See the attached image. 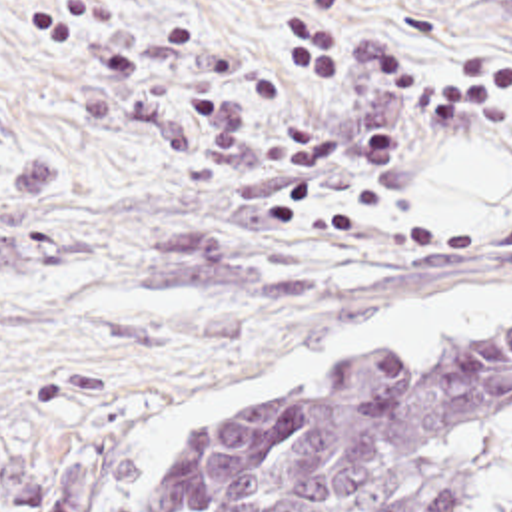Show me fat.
Wrapping results in <instances>:
<instances>
[{"mask_svg":"<svg viewBox=\"0 0 512 512\" xmlns=\"http://www.w3.org/2000/svg\"><path fill=\"white\" fill-rule=\"evenodd\" d=\"M507 193L512 195L511 157L497 145H481L421 167L417 215L425 231H463Z\"/></svg>","mask_w":512,"mask_h":512,"instance_id":"53f6f03d","label":"fat"}]
</instances>
